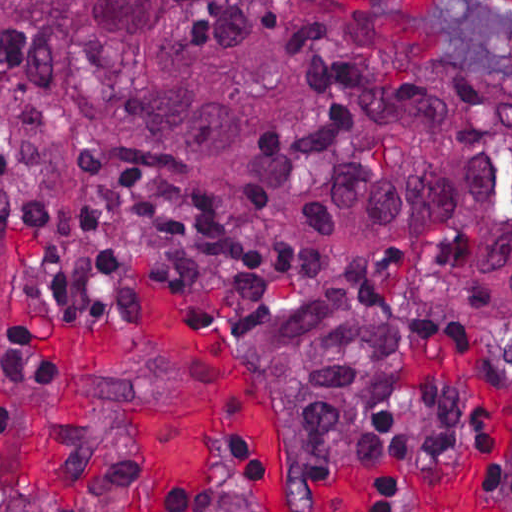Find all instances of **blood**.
Listing matches in <instances>:
<instances>
[{
    "label": "blood",
    "mask_w": 512,
    "mask_h": 512,
    "mask_svg": "<svg viewBox=\"0 0 512 512\" xmlns=\"http://www.w3.org/2000/svg\"><path fill=\"white\" fill-rule=\"evenodd\" d=\"M355 11L392 18L423 29L486 0H345ZM512 12V0H499ZM143 325L167 342L192 368L201 412L151 414L142 430V512H155L170 491L187 493V512H210L206 485L211 459L228 440L249 443L258 459L256 512H367L353 478L298 471L275 447L243 364L213 332L153 282L138 290ZM468 473H436L409 484L385 512H404L412 493L426 512H461L474 490Z\"/></svg>",
    "instance_id": "obj_1"
}]
</instances>
